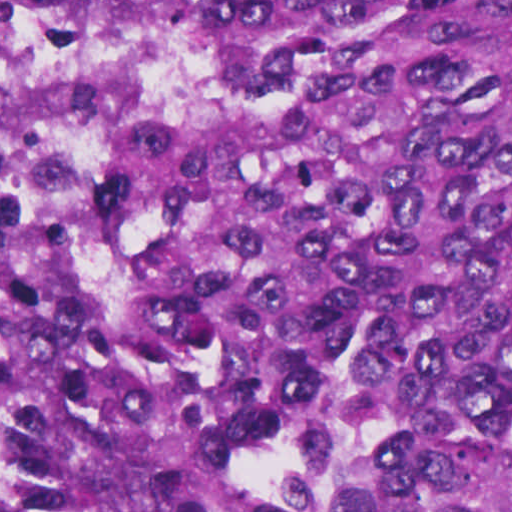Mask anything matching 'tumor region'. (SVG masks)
Listing matches in <instances>:
<instances>
[{
	"label": "tumor region",
	"instance_id": "1",
	"mask_svg": "<svg viewBox=\"0 0 512 512\" xmlns=\"http://www.w3.org/2000/svg\"><path fill=\"white\" fill-rule=\"evenodd\" d=\"M0 512H512V1H0Z\"/></svg>",
	"mask_w": 512,
	"mask_h": 512
}]
</instances>
